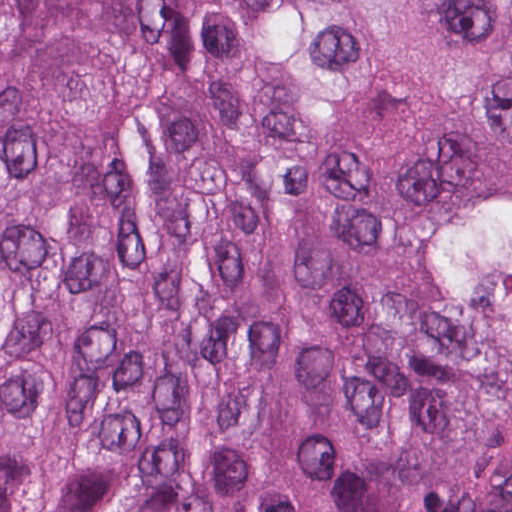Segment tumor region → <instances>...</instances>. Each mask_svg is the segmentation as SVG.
Segmentation results:
<instances>
[{
    "mask_svg": "<svg viewBox=\"0 0 512 512\" xmlns=\"http://www.w3.org/2000/svg\"><path fill=\"white\" fill-rule=\"evenodd\" d=\"M0 512H512V0H0Z\"/></svg>",
    "mask_w": 512,
    "mask_h": 512,
    "instance_id": "obj_1",
    "label": "tumor region"
}]
</instances>
